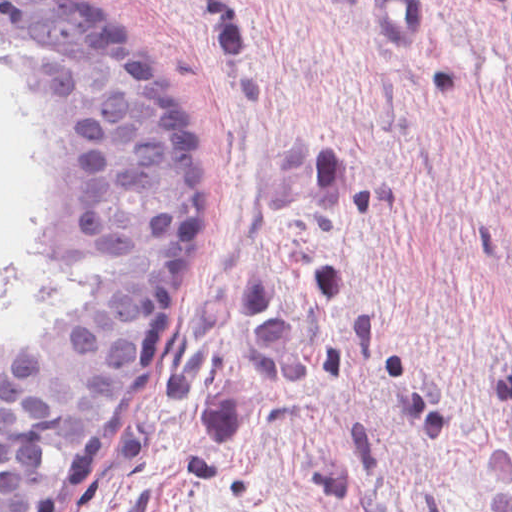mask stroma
I'll list each match as a JSON object with an SVG mask.
<instances>
[{"label": "stroma", "instance_id": "stroma-1", "mask_svg": "<svg viewBox=\"0 0 512 512\" xmlns=\"http://www.w3.org/2000/svg\"><path fill=\"white\" fill-rule=\"evenodd\" d=\"M191 113L201 311L83 512H512V0H81Z\"/></svg>", "mask_w": 512, "mask_h": 512}]
</instances>
